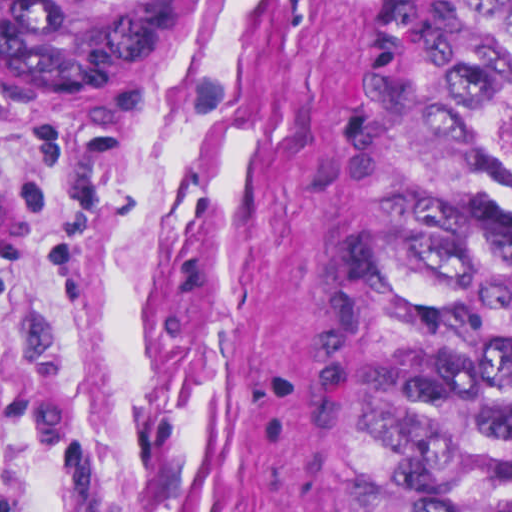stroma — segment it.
I'll return each mask as SVG.
<instances>
[{
	"mask_svg": "<svg viewBox=\"0 0 512 512\" xmlns=\"http://www.w3.org/2000/svg\"><path fill=\"white\" fill-rule=\"evenodd\" d=\"M405 0H183L125 107L0 101V512H379L369 304Z\"/></svg>",
	"mask_w": 512,
	"mask_h": 512,
	"instance_id": "35a3bbf8",
	"label": "stroma"
}]
</instances>
